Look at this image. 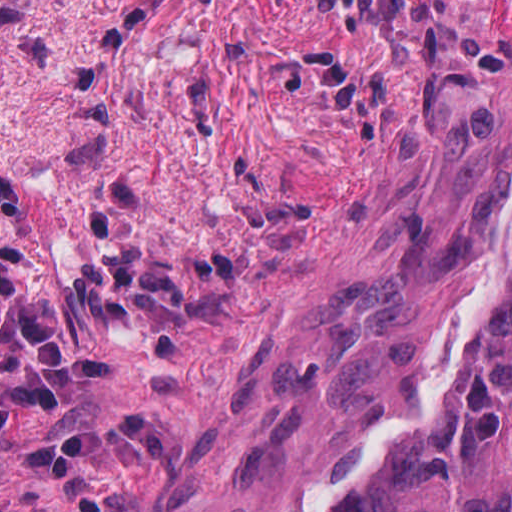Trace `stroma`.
<instances>
[{
  "instance_id": "1",
  "label": "stroma",
  "mask_w": 512,
  "mask_h": 512,
  "mask_svg": "<svg viewBox=\"0 0 512 512\" xmlns=\"http://www.w3.org/2000/svg\"><path fill=\"white\" fill-rule=\"evenodd\" d=\"M511 246L512 0H0V512H220Z\"/></svg>"
}]
</instances>
